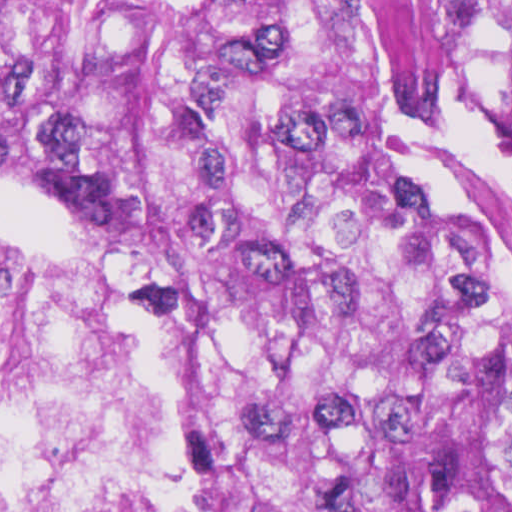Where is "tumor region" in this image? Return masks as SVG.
<instances>
[{"mask_svg":"<svg viewBox=\"0 0 512 512\" xmlns=\"http://www.w3.org/2000/svg\"><path fill=\"white\" fill-rule=\"evenodd\" d=\"M0 137L228 512H512V0H0Z\"/></svg>","mask_w":512,"mask_h":512,"instance_id":"e687c5a6","label":"tumor region"}]
</instances>
